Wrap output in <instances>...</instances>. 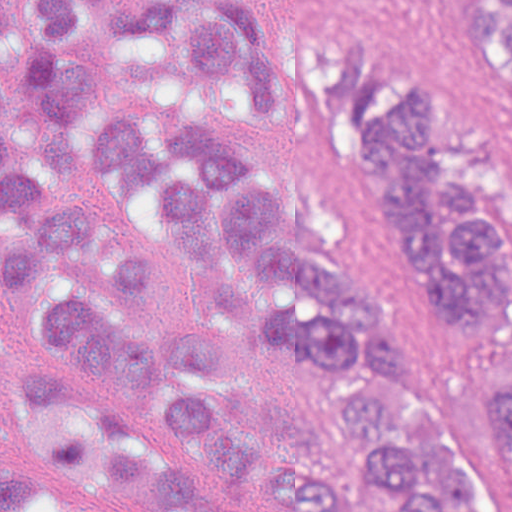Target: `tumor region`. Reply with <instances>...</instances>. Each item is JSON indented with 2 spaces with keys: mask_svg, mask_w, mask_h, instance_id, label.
Here are the masks:
<instances>
[{
  "mask_svg": "<svg viewBox=\"0 0 512 512\" xmlns=\"http://www.w3.org/2000/svg\"><path fill=\"white\" fill-rule=\"evenodd\" d=\"M249 1L0 0V282L10 292L47 276V339L98 364L0 336V512H252V437L216 377L259 339L357 378L341 389L340 426L377 455L350 483L303 451L263 455L259 477L282 512H348L350 484L368 476L393 484L397 512H482L389 324L294 252L283 196L248 149L221 122L106 102L86 135L94 182L158 189L220 303L214 323L157 334L156 355L136 300L154 296L157 273L53 190L77 183L68 125L91 91L83 33L100 29L150 33L197 83L334 134L367 161L401 269L477 365L471 434L512 512V223L456 92L328 25L266 35ZM453 2L512 78V0Z\"/></svg>",
  "mask_w": 512,
  "mask_h": 512,
  "instance_id": "e687c5a6",
  "label": "tumor region"
}]
</instances>
